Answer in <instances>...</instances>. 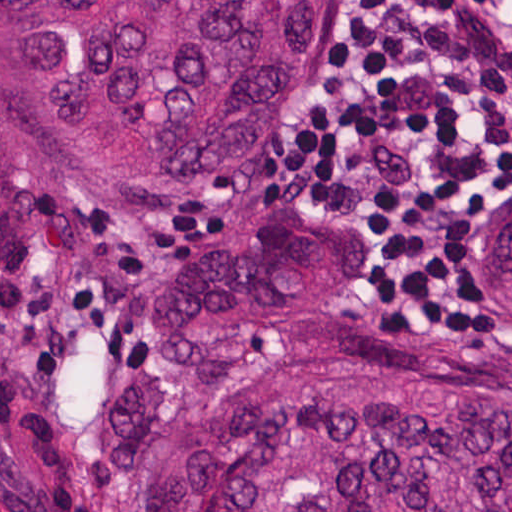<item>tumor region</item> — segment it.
<instances>
[{
    "label": "tumor region",
    "instance_id": "1",
    "mask_svg": "<svg viewBox=\"0 0 512 512\" xmlns=\"http://www.w3.org/2000/svg\"><path fill=\"white\" fill-rule=\"evenodd\" d=\"M340 0H0V269L54 192L183 207L251 161ZM464 285L512 307V208ZM178 357L112 375L151 512H512V316L382 317L317 207L193 225L150 290Z\"/></svg>",
    "mask_w": 512,
    "mask_h": 512
}]
</instances>
